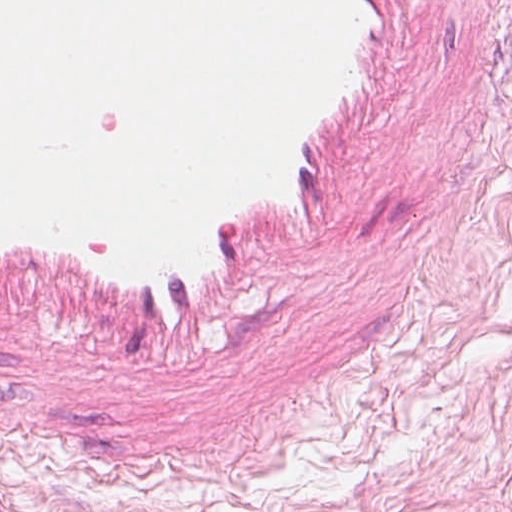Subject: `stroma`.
<instances>
[{"mask_svg":"<svg viewBox=\"0 0 512 512\" xmlns=\"http://www.w3.org/2000/svg\"><path fill=\"white\" fill-rule=\"evenodd\" d=\"M310 512H512V0H418Z\"/></svg>","mask_w":512,"mask_h":512,"instance_id":"35a3bbf8","label":"stroma"}]
</instances>
